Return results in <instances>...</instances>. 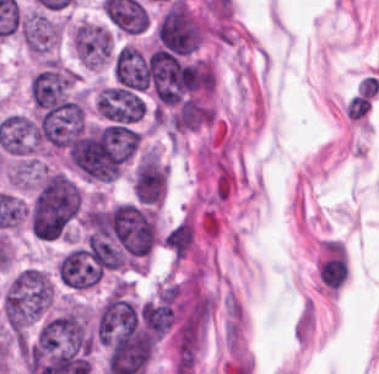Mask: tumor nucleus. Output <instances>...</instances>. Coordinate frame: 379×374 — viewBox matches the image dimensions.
<instances>
[{
  "label": "tumor nucleus",
  "mask_w": 379,
  "mask_h": 374,
  "mask_svg": "<svg viewBox=\"0 0 379 374\" xmlns=\"http://www.w3.org/2000/svg\"><path fill=\"white\" fill-rule=\"evenodd\" d=\"M57 273L73 290H88L100 281L104 272L90 250L73 248L62 258Z\"/></svg>",
  "instance_id": "4"
},
{
  "label": "tumor nucleus",
  "mask_w": 379,
  "mask_h": 374,
  "mask_svg": "<svg viewBox=\"0 0 379 374\" xmlns=\"http://www.w3.org/2000/svg\"><path fill=\"white\" fill-rule=\"evenodd\" d=\"M72 43L81 63L104 68L113 62L115 45L112 32L106 26L81 21L72 30Z\"/></svg>",
  "instance_id": "3"
},
{
  "label": "tumor nucleus",
  "mask_w": 379,
  "mask_h": 374,
  "mask_svg": "<svg viewBox=\"0 0 379 374\" xmlns=\"http://www.w3.org/2000/svg\"><path fill=\"white\" fill-rule=\"evenodd\" d=\"M53 284L37 267H24L9 280L2 298L1 311L9 328L24 329L49 309Z\"/></svg>",
  "instance_id": "2"
},
{
  "label": "tumor nucleus",
  "mask_w": 379,
  "mask_h": 374,
  "mask_svg": "<svg viewBox=\"0 0 379 374\" xmlns=\"http://www.w3.org/2000/svg\"><path fill=\"white\" fill-rule=\"evenodd\" d=\"M166 186V173L155 152L148 150L137 164L133 179V191L138 202L161 203Z\"/></svg>",
  "instance_id": "5"
},
{
  "label": "tumor nucleus",
  "mask_w": 379,
  "mask_h": 374,
  "mask_svg": "<svg viewBox=\"0 0 379 374\" xmlns=\"http://www.w3.org/2000/svg\"><path fill=\"white\" fill-rule=\"evenodd\" d=\"M83 193L62 172H49L30 207L29 222L40 237H59L82 208Z\"/></svg>",
  "instance_id": "1"
},
{
  "label": "tumor nucleus",
  "mask_w": 379,
  "mask_h": 374,
  "mask_svg": "<svg viewBox=\"0 0 379 374\" xmlns=\"http://www.w3.org/2000/svg\"><path fill=\"white\" fill-rule=\"evenodd\" d=\"M76 80L77 74L52 63L33 79L35 100L40 106H53L63 100Z\"/></svg>",
  "instance_id": "6"
},
{
  "label": "tumor nucleus",
  "mask_w": 379,
  "mask_h": 374,
  "mask_svg": "<svg viewBox=\"0 0 379 374\" xmlns=\"http://www.w3.org/2000/svg\"><path fill=\"white\" fill-rule=\"evenodd\" d=\"M114 76L122 86L147 89L148 64L143 54L132 45L120 48L115 56Z\"/></svg>",
  "instance_id": "7"
}]
</instances>
